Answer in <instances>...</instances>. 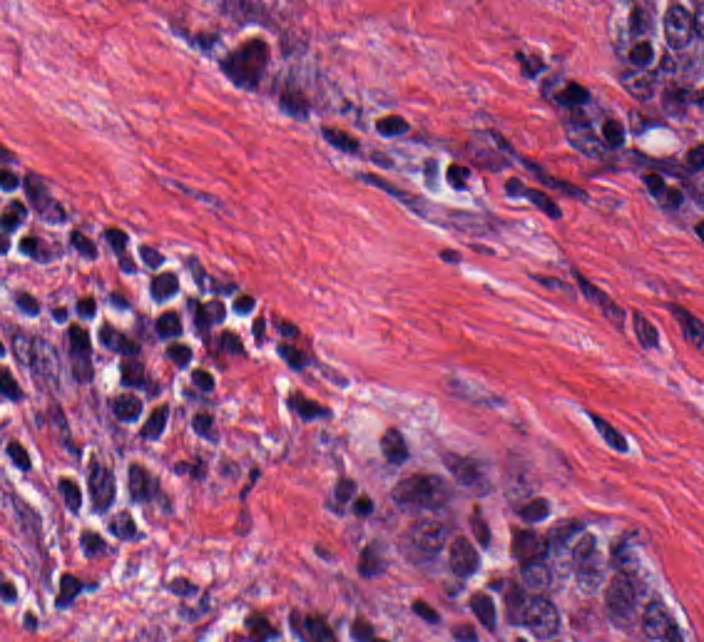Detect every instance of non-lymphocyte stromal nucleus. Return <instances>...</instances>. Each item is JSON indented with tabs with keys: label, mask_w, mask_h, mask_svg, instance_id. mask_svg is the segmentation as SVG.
Returning <instances> with one entry per match:
<instances>
[{
	"label": "non-lymphocyte stromal nucleus",
	"mask_w": 704,
	"mask_h": 642,
	"mask_svg": "<svg viewBox=\"0 0 704 642\" xmlns=\"http://www.w3.org/2000/svg\"><path fill=\"white\" fill-rule=\"evenodd\" d=\"M582 419L595 443L602 451L626 453L630 438L625 428L608 413L586 406Z\"/></svg>",
	"instance_id": "dd21d789"
}]
</instances>
